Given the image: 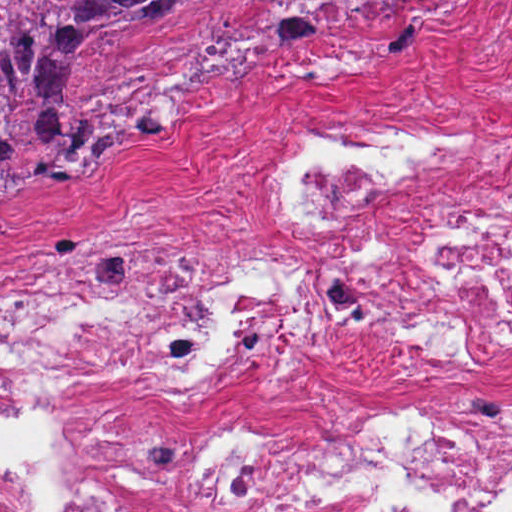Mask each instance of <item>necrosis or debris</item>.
<instances>
[{"instance_id":"4bbe7bcc","label":"necrosis or debris","mask_w":512,"mask_h":512,"mask_svg":"<svg viewBox=\"0 0 512 512\" xmlns=\"http://www.w3.org/2000/svg\"><path fill=\"white\" fill-rule=\"evenodd\" d=\"M494 151L319 123L271 187L306 238L298 267L181 261L127 217L70 258L0 273V362L77 388H184L292 319L343 305L428 359L510 352L512 205L414 255L354 241L363 209L471 174ZM30 425L53 487L0 464V512H512V390L290 427Z\"/></svg>"}]
</instances>
